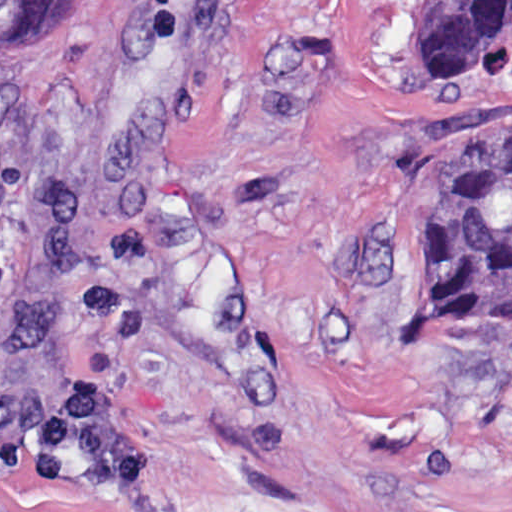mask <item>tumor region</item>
I'll return each instance as SVG.
<instances>
[{
  "label": "tumor region",
  "instance_id": "obj_1",
  "mask_svg": "<svg viewBox=\"0 0 512 512\" xmlns=\"http://www.w3.org/2000/svg\"><path fill=\"white\" fill-rule=\"evenodd\" d=\"M66 0H0V62H24L52 34ZM512 61V0H423L411 67L456 71ZM406 245V328L418 337L512 326V120L450 159Z\"/></svg>",
  "mask_w": 512,
  "mask_h": 512
}]
</instances>
